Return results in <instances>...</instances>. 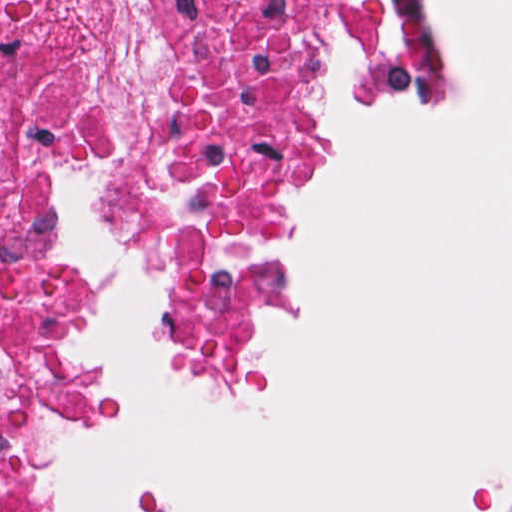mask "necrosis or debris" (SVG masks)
Wrapping results in <instances>:
<instances>
[{
    "label": "necrosis or debris",
    "mask_w": 512,
    "mask_h": 512,
    "mask_svg": "<svg viewBox=\"0 0 512 512\" xmlns=\"http://www.w3.org/2000/svg\"><path fill=\"white\" fill-rule=\"evenodd\" d=\"M161 108L121 118L64 57L0 75V512H62L33 477L43 422L82 385L79 289L62 259L50 180L104 162L121 216L160 267L196 366L233 384L247 373L254 296L304 97L293 47L373 46L375 82H405L414 22L380 1H202ZM217 25L206 37L203 31Z\"/></svg>",
    "instance_id": "1"
}]
</instances>
